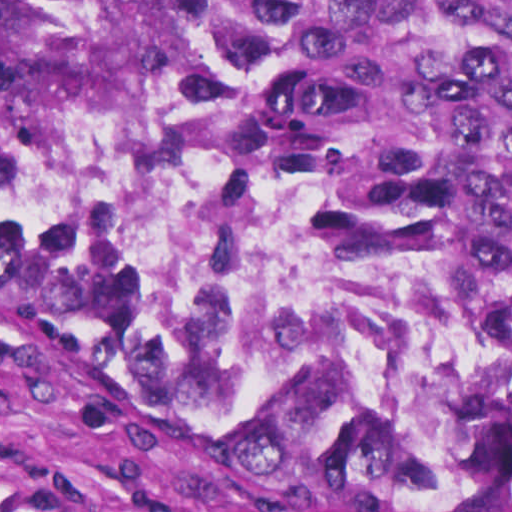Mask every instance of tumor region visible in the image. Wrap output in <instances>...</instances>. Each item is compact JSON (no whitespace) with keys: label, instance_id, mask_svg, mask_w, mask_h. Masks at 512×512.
Returning a JSON list of instances; mask_svg holds the SVG:
<instances>
[{"label":"tumor region","instance_id":"obj_1","mask_svg":"<svg viewBox=\"0 0 512 512\" xmlns=\"http://www.w3.org/2000/svg\"><path fill=\"white\" fill-rule=\"evenodd\" d=\"M0 82L107 159H263L388 218L464 299L467 353L453 393L412 416L278 430L202 376L77 215L0 169V278L38 311L308 459L512 493V0H0Z\"/></svg>","mask_w":512,"mask_h":512}]
</instances>
